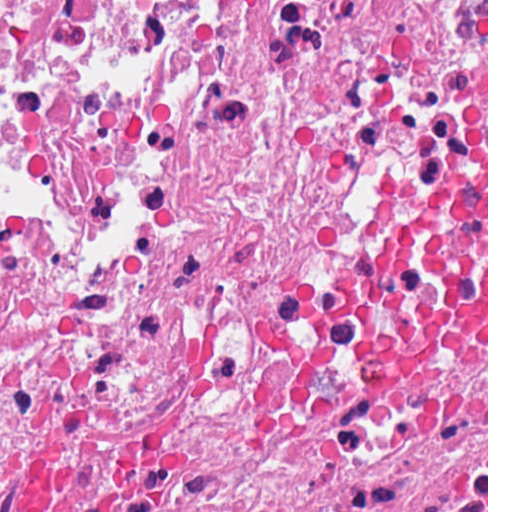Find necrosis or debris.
<instances>
[{
	"instance_id": "obj_1",
	"label": "necrosis or debris",
	"mask_w": 512,
	"mask_h": 512,
	"mask_svg": "<svg viewBox=\"0 0 512 512\" xmlns=\"http://www.w3.org/2000/svg\"><path fill=\"white\" fill-rule=\"evenodd\" d=\"M486 448V0H0V512H438Z\"/></svg>"
}]
</instances>
